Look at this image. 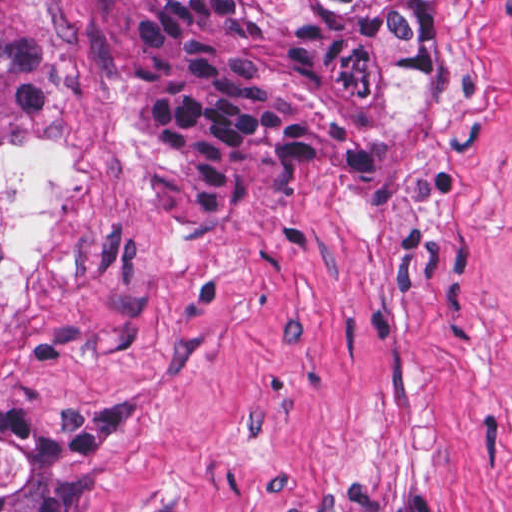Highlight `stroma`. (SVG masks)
Masks as SVG:
<instances>
[{"instance_id": "1", "label": "stroma", "mask_w": 512, "mask_h": 512, "mask_svg": "<svg viewBox=\"0 0 512 512\" xmlns=\"http://www.w3.org/2000/svg\"><path fill=\"white\" fill-rule=\"evenodd\" d=\"M46 1L65 102L0 139V507L69 438L85 512H512V0H449L419 174L276 179L203 233L138 209L140 0Z\"/></svg>"}]
</instances>
